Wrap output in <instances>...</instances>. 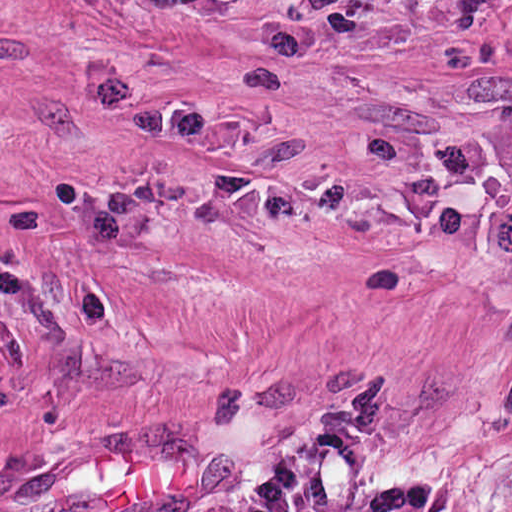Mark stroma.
Segmentation results:
<instances>
[{
	"label": "stroma",
	"instance_id": "1",
	"mask_svg": "<svg viewBox=\"0 0 512 512\" xmlns=\"http://www.w3.org/2000/svg\"><path fill=\"white\" fill-rule=\"evenodd\" d=\"M95 0H0V290Z\"/></svg>",
	"mask_w": 512,
	"mask_h": 512
}]
</instances>
